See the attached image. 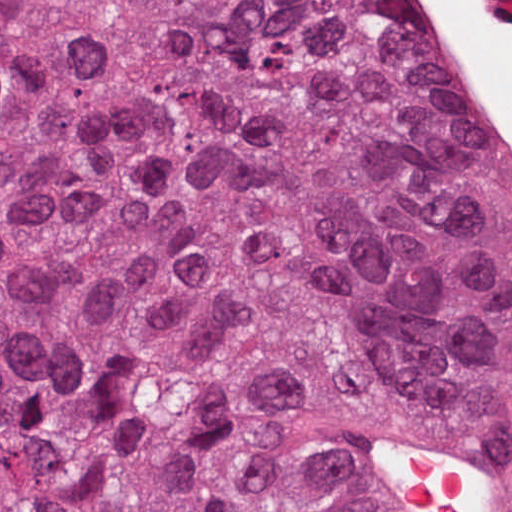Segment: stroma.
I'll return each instance as SVG.
<instances>
[{"label": "stroma", "mask_w": 512, "mask_h": 512, "mask_svg": "<svg viewBox=\"0 0 512 512\" xmlns=\"http://www.w3.org/2000/svg\"><path fill=\"white\" fill-rule=\"evenodd\" d=\"M0 1H404V0H0ZM483 104V103H482ZM484 106V105H483ZM489 124L512 179L499 134ZM406 443V444H405ZM417 456L442 461L466 473L475 485L476 512H512V463L493 448L432 424L410 412H382L366 430L363 469L379 512H437L405 494L395 467L403 446Z\"/></svg>", "instance_id": "1"}]
</instances>
